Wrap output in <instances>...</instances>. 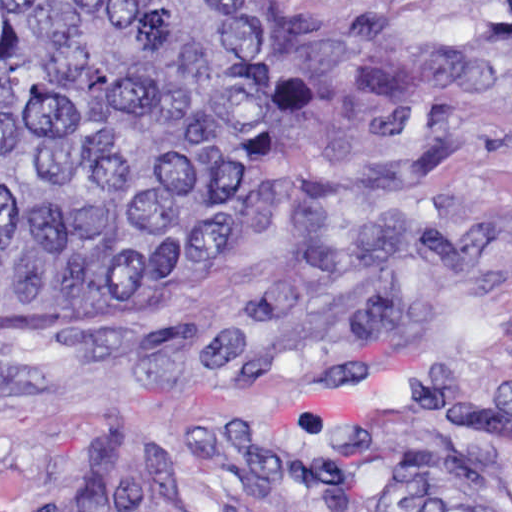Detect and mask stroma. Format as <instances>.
Instances as JSON below:
<instances>
[{"label":"stroma","mask_w":512,"mask_h":512,"mask_svg":"<svg viewBox=\"0 0 512 512\" xmlns=\"http://www.w3.org/2000/svg\"><path fill=\"white\" fill-rule=\"evenodd\" d=\"M369 45L172 300L0 295V512H512V0H268Z\"/></svg>","instance_id":"35a3bbf8"}]
</instances>
